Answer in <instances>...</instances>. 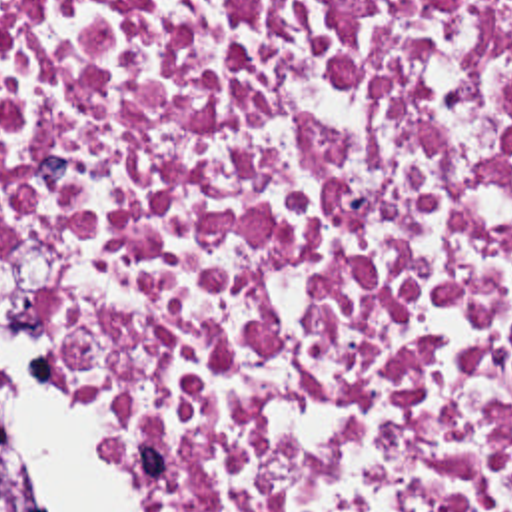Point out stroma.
Returning a JSON list of instances; mask_svg holds the SVG:
<instances>
[{"label": "stroma", "mask_w": 512, "mask_h": 512, "mask_svg": "<svg viewBox=\"0 0 512 512\" xmlns=\"http://www.w3.org/2000/svg\"><path fill=\"white\" fill-rule=\"evenodd\" d=\"M0 245H6V247H8V249H10V253H12V257H14V241H12V237H10V231H8V227H6V225H4V227H0ZM26 315H28V313H26ZM28 319H30V317H28ZM30 323H32V329H34V333H38V327H36V325H34V321H32V319H30ZM46 379H50V381H52V383H56V385H58V387H62V389H64V391H68V393H72V395H76V397H80V399H84V401L90 402V404H92V406H96V408H98V410H100V412H102V406H100V402L96 401V399H92V397H86V395H82V393H78V391H74V389H70V387H68V385H64V383H60V381H58V379H54V377H50V375H48V373H46ZM102 414H104V412H102ZM144 494H146V492H144ZM146 498H148V496H146ZM148 502H150V506H152V510H154V512H158V510H156V508H154V504H152V500H150V498H148Z\"/></svg>", "instance_id": "stroma-1"}]
</instances>
